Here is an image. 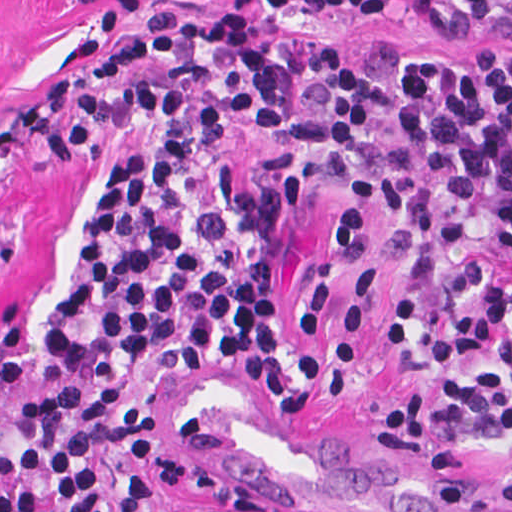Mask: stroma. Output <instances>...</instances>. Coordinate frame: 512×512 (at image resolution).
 Instances as JSON below:
<instances>
[{
  "label": "stroma",
  "mask_w": 512,
  "mask_h": 512,
  "mask_svg": "<svg viewBox=\"0 0 512 512\" xmlns=\"http://www.w3.org/2000/svg\"><path fill=\"white\" fill-rule=\"evenodd\" d=\"M163 11L201 20L251 18L270 43H341L360 54L391 37L420 56H466L500 43L512 60V0H0V122L67 74L91 51ZM123 154L170 165L182 186L164 222L181 231L190 211L217 193L215 168L238 189L272 185L291 170L300 190L278 215L282 250L275 317L289 338V364L314 387V410L288 408L244 359H216L187 375L155 372L122 401L161 413L153 433L103 449L96 479L104 512L115 511L117 453L133 438L155 442L188 419L224 433L223 449L199 454L306 512H509L496 494L512 451L491 443L463 451H412L373 425L378 401L437 375H487L499 352L399 368L389 310L409 262L383 250L378 233L398 219L370 184L322 180L310 161L286 152L265 123H241L222 152L185 151L163 118L137 122L81 154L0 164V323L21 308L26 374L0 399V451L17 449L21 412L48 394L44 327L67 302L107 174ZM199 494L163 489L153 472L145 512L216 507Z\"/></svg>",
  "instance_id": "obj_1"
}]
</instances>
